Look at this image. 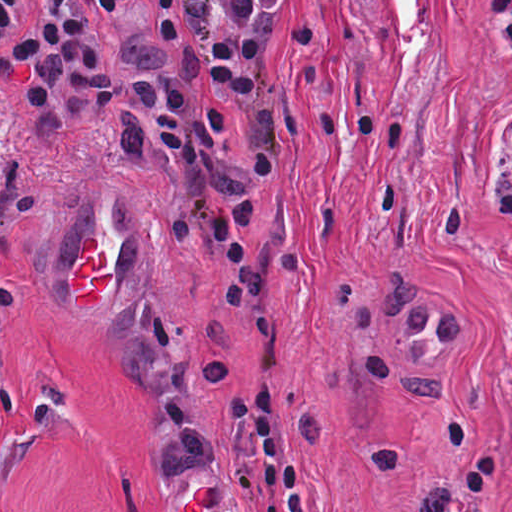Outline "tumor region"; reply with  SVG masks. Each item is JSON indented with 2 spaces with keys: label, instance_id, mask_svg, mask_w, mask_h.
<instances>
[{
  "label": "tumor region",
  "instance_id": "obj_1",
  "mask_svg": "<svg viewBox=\"0 0 512 512\" xmlns=\"http://www.w3.org/2000/svg\"><path fill=\"white\" fill-rule=\"evenodd\" d=\"M127 298H153V295L137 286L132 289L109 295L100 302L97 319L108 337L113 321Z\"/></svg>",
  "mask_w": 512,
  "mask_h": 512
}]
</instances>
